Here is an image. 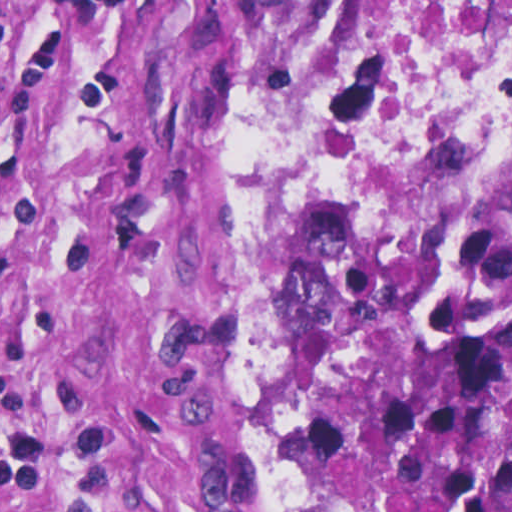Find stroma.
Masks as SVG:
<instances>
[{"label": "stroma", "mask_w": 512, "mask_h": 512, "mask_svg": "<svg viewBox=\"0 0 512 512\" xmlns=\"http://www.w3.org/2000/svg\"><path fill=\"white\" fill-rule=\"evenodd\" d=\"M302 1L0 0V512H258Z\"/></svg>", "instance_id": "35a3bbf8"}]
</instances>
